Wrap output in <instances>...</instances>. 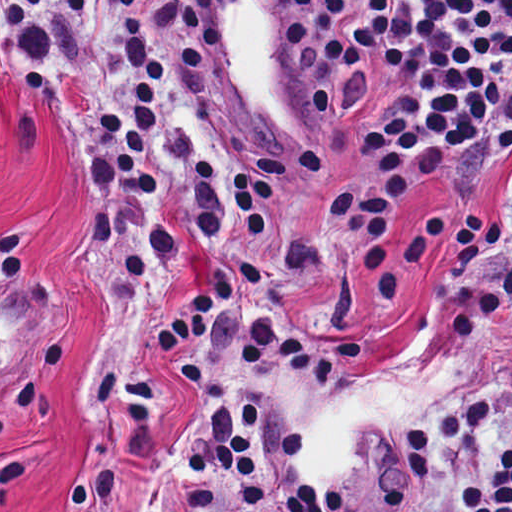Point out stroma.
<instances>
[{"mask_svg":"<svg viewBox=\"0 0 512 512\" xmlns=\"http://www.w3.org/2000/svg\"><path fill=\"white\" fill-rule=\"evenodd\" d=\"M212 1L230 117L278 140L331 142L336 174L282 207L263 265L193 241L158 304L112 306L92 280L103 182L66 124L51 4L0 61V512H173L193 413L154 334L172 329L199 280H234L318 331L360 338L386 365L418 356L442 311L510 253L512 166L475 208L409 192L393 223L398 298H363L358 247L330 231L360 161L304 92L286 0Z\"/></svg>","mask_w":512,"mask_h":512,"instance_id":"1","label":"stroma"}]
</instances>
